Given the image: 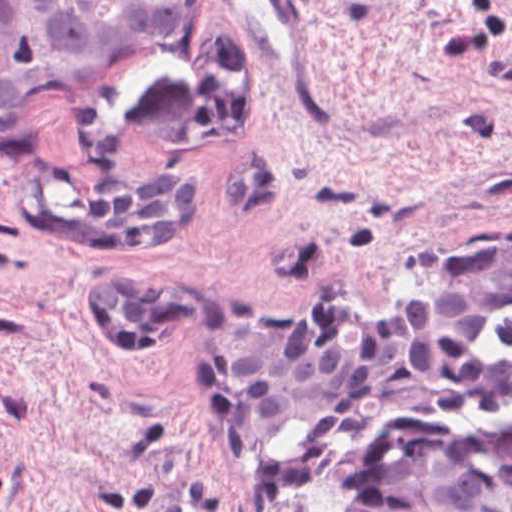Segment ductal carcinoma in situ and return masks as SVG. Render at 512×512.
<instances>
[{
    "label": "ductal carcinoma in situ",
    "mask_w": 512,
    "mask_h": 512,
    "mask_svg": "<svg viewBox=\"0 0 512 512\" xmlns=\"http://www.w3.org/2000/svg\"><path fill=\"white\" fill-rule=\"evenodd\" d=\"M182 0H0V153L28 150L30 104L157 45ZM356 512H512V420H413L362 459Z\"/></svg>",
    "instance_id": "ductal-carcinoma-in-situ-1"
}]
</instances>
